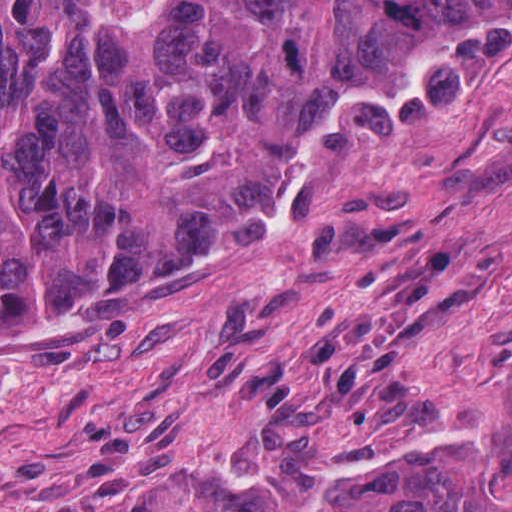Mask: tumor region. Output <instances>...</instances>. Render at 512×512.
I'll list each match as a JSON object with an SVG mask.
<instances>
[{
	"label": "tumor region",
	"instance_id": "obj_1",
	"mask_svg": "<svg viewBox=\"0 0 512 512\" xmlns=\"http://www.w3.org/2000/svg\"><path fill=\"white\" fill-rule=\"evenodd\" d=\"M512 23V1H0V329L284 204L317 114ZM100 512H512V410L302 477L166 471Z\"/></svg>",
	"mask_w": 512,
	"mask_h": 512
}]
</instances>
